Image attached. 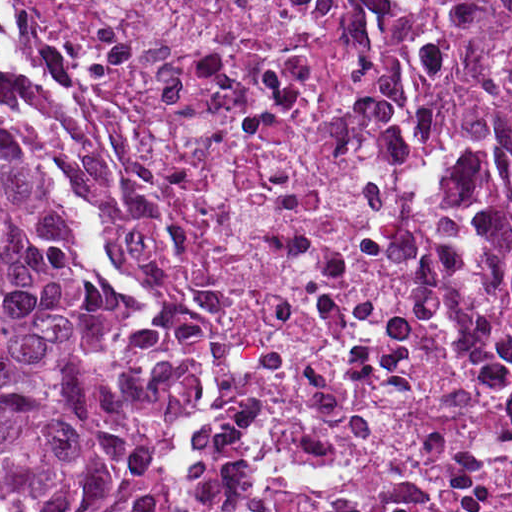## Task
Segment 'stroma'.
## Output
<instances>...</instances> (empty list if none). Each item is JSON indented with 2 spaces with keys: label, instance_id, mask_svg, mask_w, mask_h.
<instances>
[{
  "label": "stroma",
  "instance_id": "35a3bbf8",
  "mask_svg": "<svg viewBox=\"0 0 512 512\" xmlns=\"http://www.w3.org/2000/svg\"><path fill=\"white\" fill-rule=\"evenodd\" d=\"M424 13L460 31L494 38H512V23L487 18H470L461 26L445 20L434 0H416ZM0 126L16 150L33 166L42 178L57 189L67 203L74 227V246L79 258L90 268L97 284L118 303L148 313L155 325V342L144 352L167 370L178 360L191 357L193 376L191 399L186 418L166 433L160 447L173 468V499L166 512H188L190 501L185 470L190 460V440L201 421L209 413L214 388V368L211 355L180 353L173 339L162 326V309L152 300L135 297L127 286L97 266L88 247L84 221L73 192L33 153L23 128L11 110L0 99Z\"/></svg>",
  "mask_w": 512,
  "mask_h": 512
}]
</instances>
